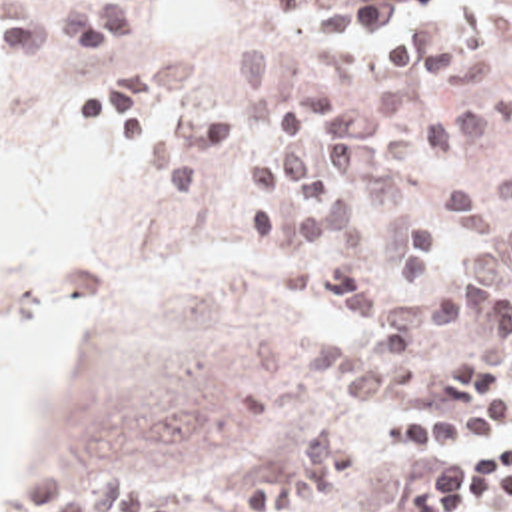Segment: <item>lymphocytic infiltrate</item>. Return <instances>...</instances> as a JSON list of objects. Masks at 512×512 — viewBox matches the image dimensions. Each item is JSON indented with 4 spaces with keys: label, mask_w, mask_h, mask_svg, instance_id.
I'll return each mask as SVG.
<instances>
[{
    "label": "lymphocytic infiltrate",
    "mask_w": 512,
    "mask_h": 512,
    "mask_svg": "<svg viewBox=\"0 0 512 512\" xmlns=\"http://www.w3.org/2000/svg\"><path fill=\"white\" fill-rule=\"evenodd\" d=\"M505 339L512 347V295ZM443 395L455 409L449 417H397L377 431L391 453L425 455L401 512H463L512 499V373L471 355L443 373Z\"/></svg>",
    "instance_id": "obj_1"
}]
</instances>
